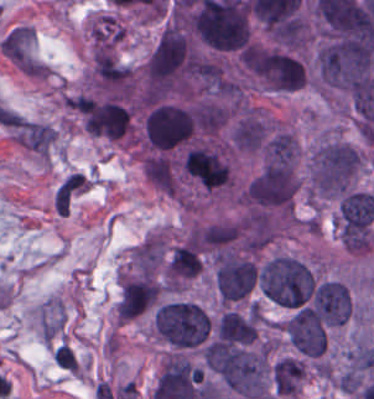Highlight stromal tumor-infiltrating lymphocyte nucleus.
Masks as SVG:
<instances>
[{
    "label": "stromal tumor-infiltrating lymphocyte nucleus",
    "mask_w": 374,
    "mask_h": 399,
    "mask_svg": "<svg viewBox=\"0 0 374 399\" xmlns=\"http://www.w3.org/2000/svg\"><path fill=\"white\" fill-rule=\"evenodd\" d=\"M53 357L59 366L77 373L79 364L69 344L63 343Z\"/></svg>",
    "instance_id": "stromal-tumor-infiltrating-lymphocyte-nucleus-1"
}]
</instances>
